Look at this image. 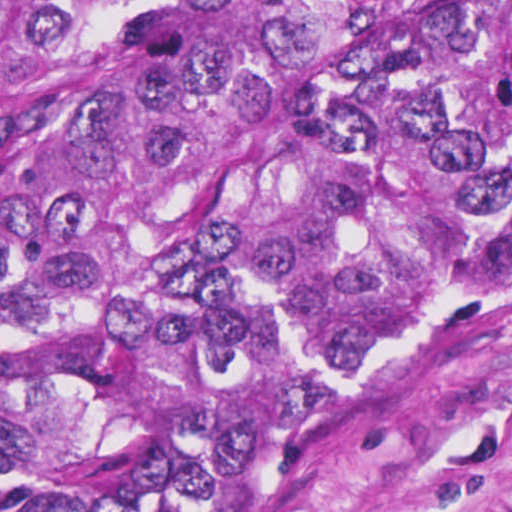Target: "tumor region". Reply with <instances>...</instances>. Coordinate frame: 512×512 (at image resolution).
Returning a JSON list of instances; mask_svg holds the SVG:
<instances>
[{"mask_svg":"<svg viewBox=\"0 0 512 512\" xmlns=\"http://www.w3.org/2000/svg\"><path fill=\"white\" fill-rule=\"evenodd\" d=\"M512 287V0H0V512H295Z\"/></svg>","mask_w":512,"mask_h":512,"instance_id":"e687c5a6","label":"tumor region"}]
</instances>
